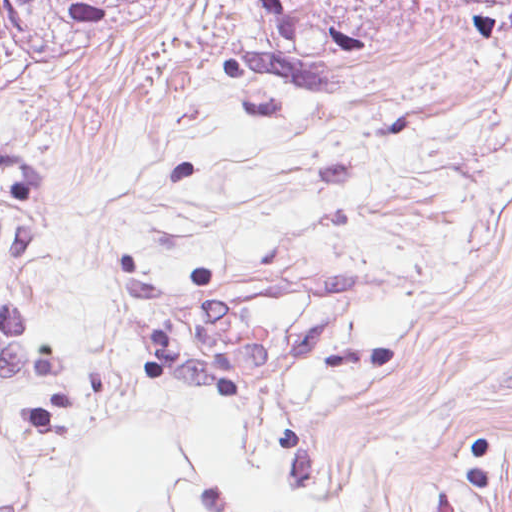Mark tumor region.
<instances>
[{
	"instance_id": "tumor-region-1",
	"label": "tumor region",
	"mask_w": 512,
	"mask_h": 512,
	"mask_svg": "<svg viewBox=\"0 0 512 512\" xmlns=\"http://www.w3.org/2000/svg\"><path fill=\"white\" fill-rule=\"evenodd\" d=\"M127 0H2L0 54L82 63L112 49ZM59 215L41 170L0 151V391Z\"/></svg>"
}]
</instances>
